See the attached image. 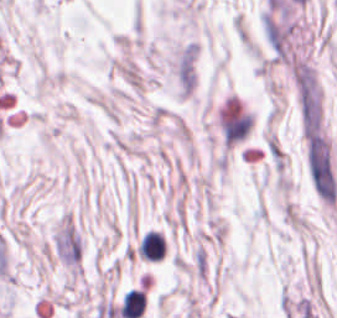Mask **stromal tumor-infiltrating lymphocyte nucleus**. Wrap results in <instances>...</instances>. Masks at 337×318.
I'll return each mask as SVG.
<instances>
[{"instance_id": "stromal-tumor-infiltrating-lymphocyte-nucleus-1", "label": "stromal tumor-infiltrating lymphocyte nucleus", "mask_w": 337, "mask_h": 318, "mask_svg": "<svg viewBox=\"0 0 337 318\" xmlns=\"http://www.w3.org/2000/svg\"><path fill=\"white\" fill-rule=\"evenodd\" d=\"M137 253L145 260L160 261L165 253L164 237L148 230L139 240Z\"/></svg>"}, {"instance_id": "stromal-tumor-infiltrating-lymphocyte-nucleus-2", "label": "stromal tumor-infiltrating lymphocyte nucleus", "mask_w": 337, "mask_h": 318, "mask_svg": "<svg viewBox=\"0 0 337 318\" xmlns=\"http://www.w3.org/2000/svg\"><path fill=\"white\" fill-rule=\"evenodd\" d=\"M145 309L143 291L131 289L121 299L119 306L122 318H139Z\"/></svg>"}]
</instances>
